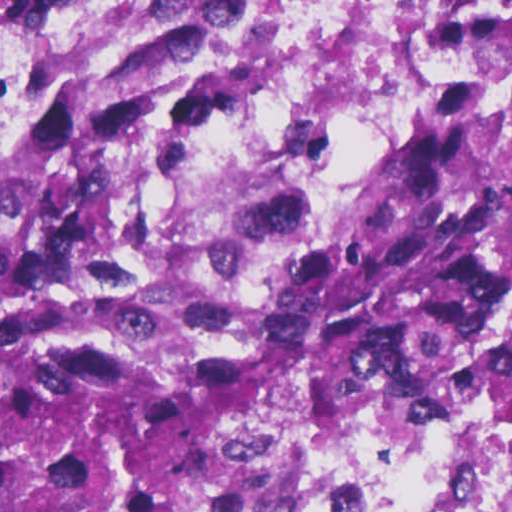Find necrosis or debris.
Masks as SVG:
<instances>
[{
  "instance_id": "necrosis-or-debris-1",
  "label": "necrosis or debris",
  "mask_w": 512,
  "mask_h": 512,
  "mask_svg": "<svg viewBox=\"0 0 512 512\" xmlns=\"http://www.w3.org/2000/svg\"><path fill=\"white\" fill-rule=\"evenodd\" d=\"M156 0H0V135ZM512 104V0H263L194 161L235 245L359 210L453 102ZM242 512H512V289L462 342L267 472Z\"/></svg>"
}]
</instances>
